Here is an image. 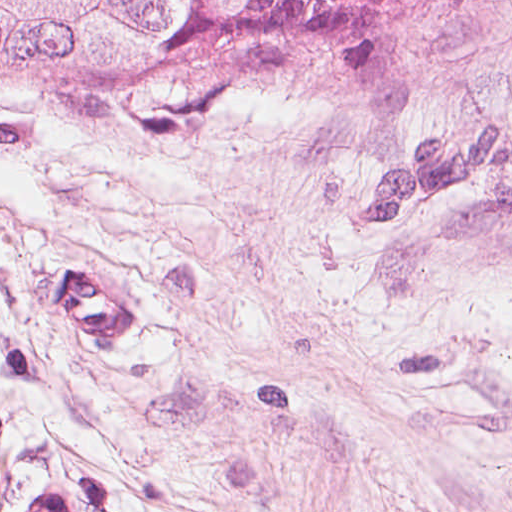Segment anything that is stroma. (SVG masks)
I'll list each match as a JSON object with an SVG mask.
<instances>
[{"instance_id":"1","label":"stroma","mask_w":512,"mask_h":512,"mask_svg":"<svg viewBox=\"0 0 512 512\" xmlns=\"http://www.w3.org/2000/svg\"><path fill=\"white\" fill-rule=\"evenodd\" d=\"M145 298L76 355L49 281ZM512 512V0L155 138L0 88V512Z\"/></svg>"}]
</instances>
